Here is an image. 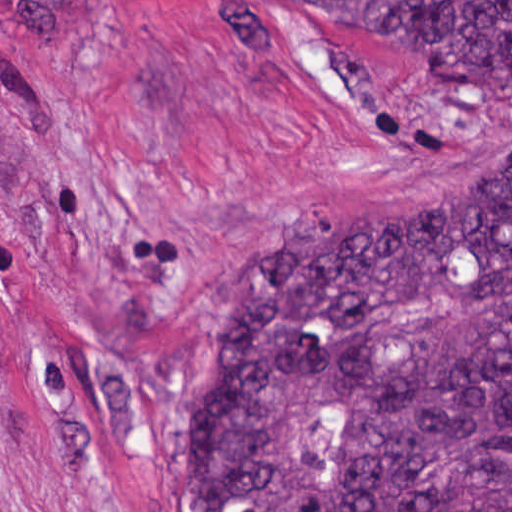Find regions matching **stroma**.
<instances>
[{"label":"stroma","instance_id":"stroma-1","mask_svg":"<svg viewBox=\"0 0 512 512\" xmlns=\"http://www.w3.org/2000/svg\"><path fill=\"white\" fill-rule=\"evenodd\" d=\"M505 158L512 80H430L340 8L87 0L48 38L0 27V512H190L243 272Z\"/></svg>","mask_w":512,"mask_h":512}]
</instances>
